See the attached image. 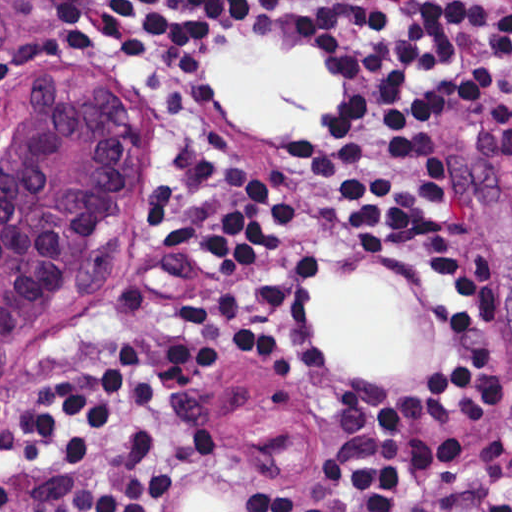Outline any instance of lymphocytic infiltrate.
Wrapping results in <instances>:
<instances>
[{
  "mask_svg": "<svg viewBox=\"0 0 512 512\" xmlns=\"http://www.w3.org/2000/svg\"><path fill=\"white\" fill-rule=\"evenodd\" d=\"M29 1L84 47L154 65L263 29L289 5ZM324 1L345 15L310 32L309 51L345 72V89L299 139L296 192L410 277L444 356L327 420L291 496L234 512H512L504 377L475 336L498 290L490 254L460 257L462 211L437 164L439 118L461 106L512 174V0ZM319 271L244 157L178 166L148 287L0 418V512H178L187 476L219 446L206 361L258 364L295 389L323 376Z\"/></svg>",
  "mask_w": 512,
  "mask_h": 512,
  "instance_id": "obj_1",
  "label": "lymphocytic infiltrate"
}]
</instances>
